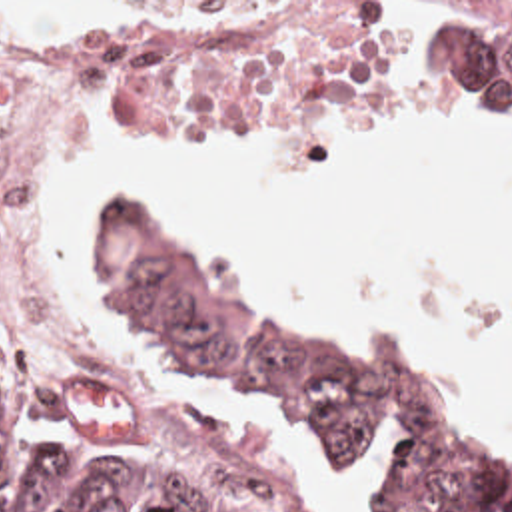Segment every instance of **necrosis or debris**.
<instances>
[{"mask_svg": "<svg viewBox=\"0 0 512 512\" xmlns=\"http://www.w3.org/2000/svg\"><path fill=\"white\" fill-rule=\"evenodd\" d=\"M404 2H0V319L45 321L7 232V148L45 78L172 94H312L384 68Z\"/></svg>", "mask_w": 512, "mask_h": 512, "instance_id": "necrosis-or-debris-1", "label": "necrosis or debris"}]
</instances>
